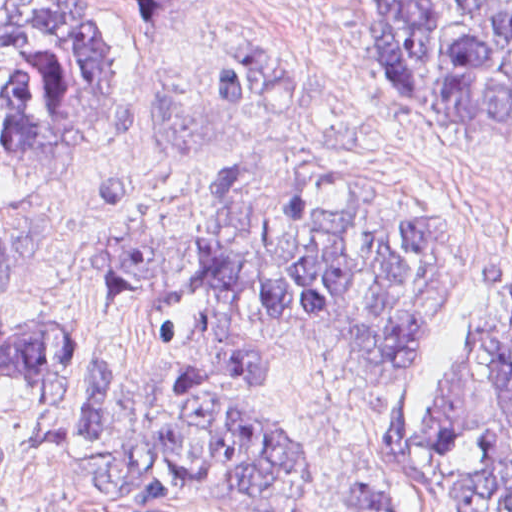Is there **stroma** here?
Listing matches in <instances>:
<instances>
[{"label":"stroma","instance_id":"35a3bbf8","mask_svg":"<svg viewBox=\"0 0 512 512\" xmlns=\"http://www.w3.org/2000/svg\"><path fill=\"white\" fill-rule=\"evenodd\" d=\"M374 1L114 4L122 143L77 163H0V233L13 250V298L0 312V334L35 323L71 330L76 369L56 428H69L84 401L88 361H104L108 391L136 397L149 379L137 286L97 271L84 236L167 232L196 219L212 187L246 162H308L440 213L437 324L417 339L425 342L362 364L287 328L277 361L210 384L262 407L311 454L318 486L296 512H333L354 485L394 490L406 512H471L426 491L413 475V449L448 347L461 333L512 339V142L465 139L449 109L399 95ZM244 35L303 49L305 92L270 120L224 122L204 100L199 63L212 46ZM39 413L31 388L0 375V440L17 466L0 512H231L190 500L177 471L149 455L169 481L166 504L130 509L100 497L81 461L24 446Z\"/></svg>","mask_w":512,"mask_h":512}]
</instances>
